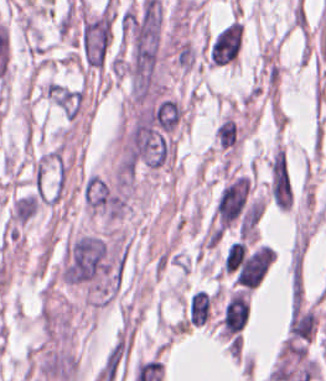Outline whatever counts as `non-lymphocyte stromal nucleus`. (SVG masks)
<instances>
[{
  "mask_svg": "<svg viewBox=\"0 0 326 381\" xmlns=\"http://www.w3.org/2000/svg\"><path fill=\"white\" fill-rule=\"evenodd\" d=\"M210 306V294L207 292L197 289L190 294L189 323L201 326L208 319Z\"/></svg>",
  "mask_w": 326,
  "mask_h": 381,
  "instance_id": "obj_2",
  "label": "non-lymphocyte stromal nucleus"
},
{
  "mask_svg": "<svg viewBox=\"0 0 326 381\" xmlns=\"http://www.w3.org/2000/svg\"><path fill=\"white\" fill-rule=\"evenodd\" d=\"M243 25L236 19L227 24L212 40L209 65H221L236 60L241 40Z\"/></svg>",
  "mask_w": 326,
  "mask_h": 381,
  "instance_id": "obj_1",
  "label": "non-lymphocyte stromal nucleus"
}]
</instances>
